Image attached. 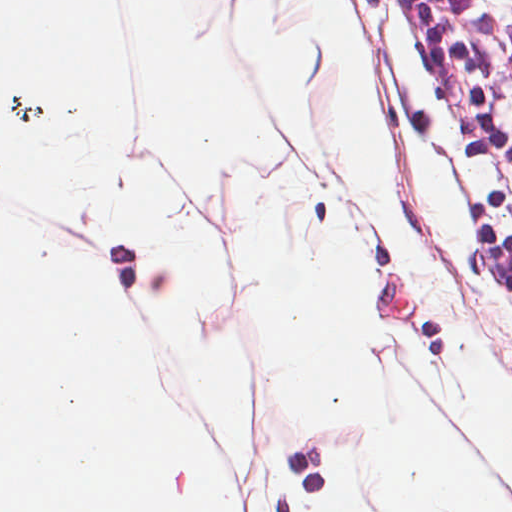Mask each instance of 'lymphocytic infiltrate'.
<instances>
[{
    "label": "lymphocytic infiltrate",
    "instance_id": "1",
    "mask_svg": "<svg viewBox=\"0 0 512 512\" xmlns=\"http://www.w3.org/2000/svg\"><path fill=\"white\" fill-rule=\"evenodd\" d=\"M512 75V0H463Z\"/></svg>",
    "mask_w": 512,
    "mask_h": 512
}]
</instances>
